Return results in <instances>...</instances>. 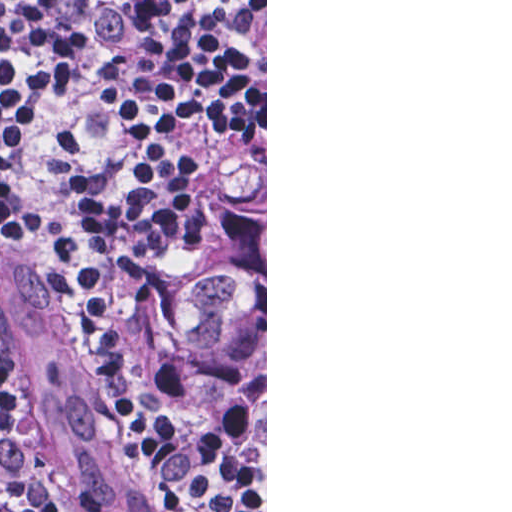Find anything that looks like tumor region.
Wrapping results in <instances>:
<instances>
[{"instance_id":"obj_1","label":"tumor region","mask_w":512,"mask_h":512,"mask_svg":"<svg viewBox=\"0 0 512 512\" xmlns=\"http://www.w3.org/2000/svg\"><path fill=\"white\" fill-rule=\"evenodd\" d=\"M120 335L152 407L207 464L265 506V158L235 166L205 206L181 278L164 300L128 318ZM18 396L48 512H57ZM112 415L149 500L158 512H171L131 458Z\"/></svg>"}]
</instances>
